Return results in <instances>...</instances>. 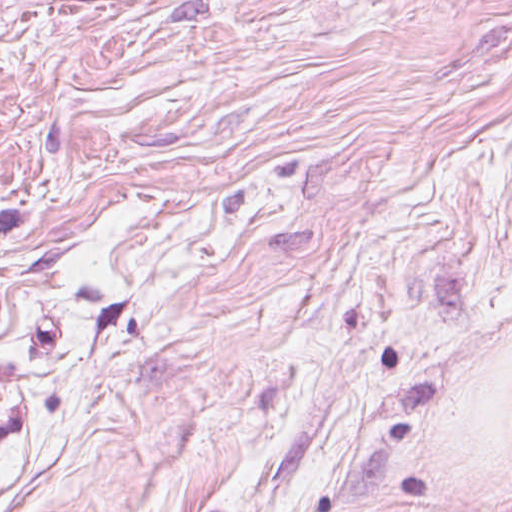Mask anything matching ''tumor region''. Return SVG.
<instances>
[{"label": "tumor region", "mask_w": 512, "mask_h": 512, "mask_svg": "<svg viewBox=\"0 0 512 512\" xmlns=\"http://www.w3.org/2000/svg\"><path fill=\"white\" fill-rule=\"evenodd\" d=\"M54 0H0V11L3 9H21Z\"/></svg>", "instance_id": "tumor-region-1"}]
</instances>
